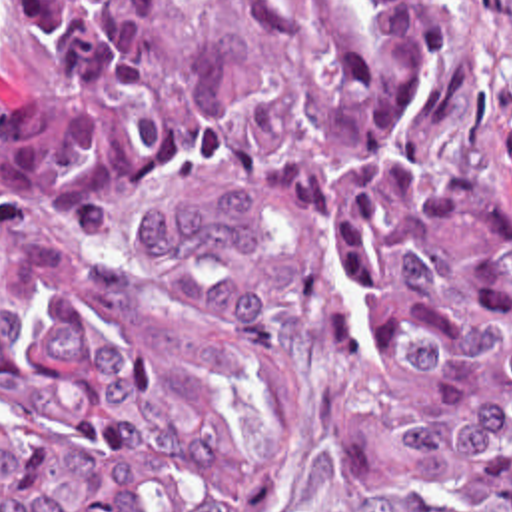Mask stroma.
Masks as SVG:
<instances>
[{
	"mask_svg": "<svg viewBox=\"0 0 512 512\" xmlns=\"http://www.w3.org/2000/svg\"><path fill=\"white\" fill-rule=\"evenodd\" d=\"M457 58L433 140V170L512 200V0H453ZM30 98L22 2L0 0V120ZM243 512H383L341 471L315 413L309 331L291 341L273 457Z\"/></svg>",
	"mask_w": 512,
	"mask_h": 512,
	"instance_id": "obj_1",
	"label": "stroma"
}]
</instances>
